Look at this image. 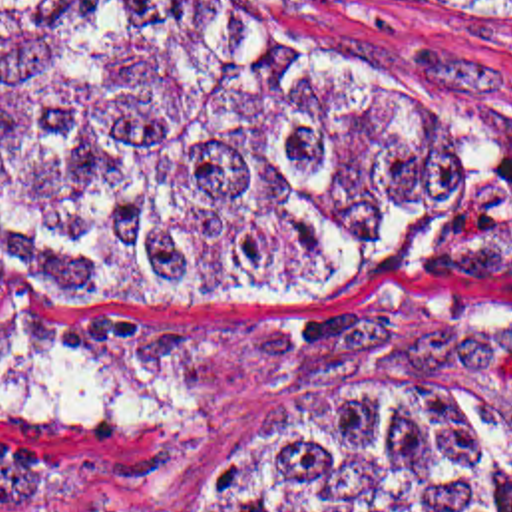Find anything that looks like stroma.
<instances>
[{
    "label": "stroma",
    "mask_w": 512,
    "mask_h": 512,
    "mask_svg": "<svg viewBox=\"0 0 512 512\" xmlns=\"http://www.w3.org/2000/svg\"><path fill=\"white\" fill-rule=\"evenodd\" d=\"M408 93L434 180L352 256L216 298L0 282V465L93 489L0 512H199L224 449L304 393L432 385L512 411V3L248 0L236 13Z\"/></svg>",
    "instance_id": "1"
}]
</instances>
